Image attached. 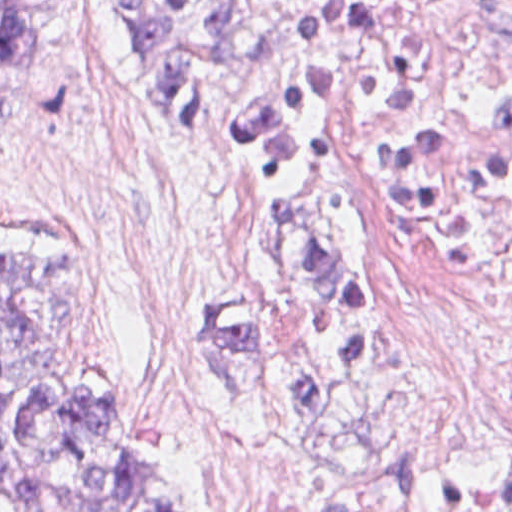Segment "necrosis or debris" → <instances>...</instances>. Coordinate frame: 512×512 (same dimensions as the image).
Returning a JSON list of instances; mask_svg holds the SVG:
<instances>
[{"mask_svg":"<svg viewBox=\"0 0 512 512\" xmlns=\"http://www.w3.org/2000/svg\"><path fill=\"white\" fill-rule=\"evenodd\" d=\"M366 261L406 438L512 444V0H461L391 70L346 77ZM219 512H450L247 441Z\"/></svg>","mask_w":512,"mask_h":512,"instance_id":"necrosis-or-debris-1","label":"necrosis or debris"}]
</instances>
